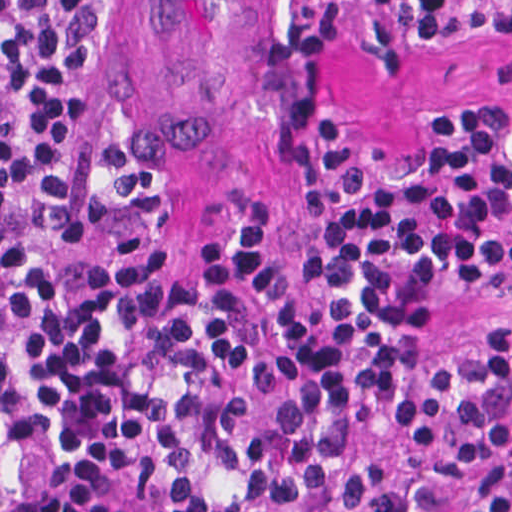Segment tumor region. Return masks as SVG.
I'll list each match as a JSON object with an SVG mask.
<instances>
[{"mask_svg": "<svg viewBox=\"0 0 512 512\" xmlns=\"http://www.w3.org/2000/svg\"><path fill=\"white\" fill-rule=\"evenodd\" d=\"M0 512H70L39 459L0 426Z\"/></svg>", "mask_w": 512, "mask_h": 512, "instance_id": "e687c5a6", "label": "tumor region"}]
</instances>
